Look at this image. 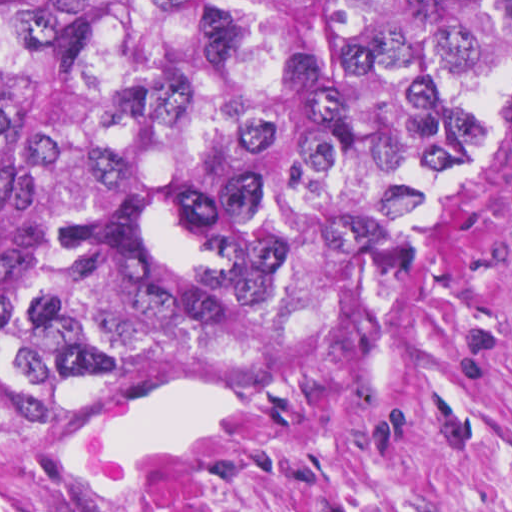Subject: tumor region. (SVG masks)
<instances>
[{
  "mask_svg": "<svg viewBox=\"0 0 512 512\" xmlns=\"http://www.w3.org/2000/svg\"><path fill=\"white\" fill-rule=\"evenodd\" d=\"M492 69L447 1H0V416L382 286Z\"/></svg>",
  "mask_w": 512,
  "mask_h": 512,
  "instance_id": "obj_1",
  "label": "tumor region"
}]
</instances>
